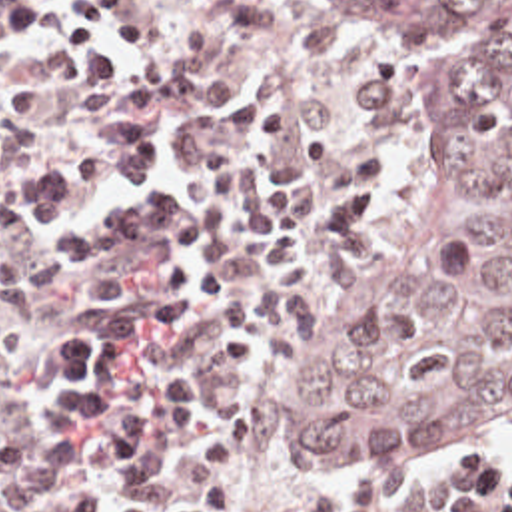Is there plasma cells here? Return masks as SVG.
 <instances>
[{
    "instance_id": "plasma-cells-1",
    "label": "plasma cells",
    "mask_w": 512,
    "mask_h": 512,
    "mask_svg": "<svg viewBox=\"0 0 512 512\" xmlns=\"http://www.w3.org/2000/svg\"><path fill=\"white\" fill-rule=\"evenodd\" d=\"M115 111L157 113L169 135L199 123L233 129L249 157L251 293L281 335H295L384 199L390 81L354 61L341 35L281 5L205 0L201 35L139 79L0 85V117L29 113L61 131ZM41 145L31 127L0 135V369L23 351L19 313L51 297V277L7 215V187ZM81 468L75 440L3 438L0 512H91V494L75 484ZM289 512H492V460L440 456L412 482H354Z\"/></svg>"
}]
</instances>
